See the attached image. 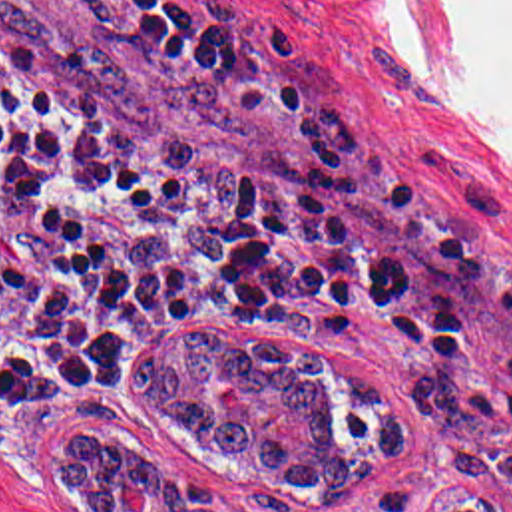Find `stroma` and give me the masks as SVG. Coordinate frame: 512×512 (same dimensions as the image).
<instances>
[{"label": "stroma", "mask_w": 512, "mask_h": 512, "mask_svg": "<svg viewBox=\"0 0 512 512\" xmlns=\"http://www.w3.org/2000/svg\"><path fill=\"white\" fill-rule=\"evenodd\" d=\"M208 21L264 65L340 111L405 208L445 246L512 280V151L453 105L439 61L395 0H198ZM0 61L97 121L300 230H318L300 155L282 125L234 91H210L127 59L61 0H0ZM270 334L310 346L403 404L413 443L376 467L358 499H310L254 481L244 463L184 443L137 392L135 354L174 330ZM240 382L212 402L242 412ZM69 439L154 453L176 477L216 485L224 512H439L483 495L512 509V322H473L451 350L407 360L328 324H147L117 352L105 390L0 422V512H89L61 479ZM117 501L149 509V483L119 477Z\"/></svg>", "instance_id": "35a3bbf8"}]
</instances>
